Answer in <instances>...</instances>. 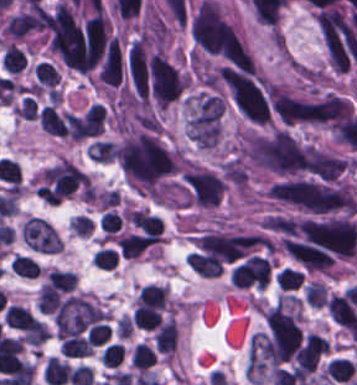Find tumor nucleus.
Listing matches in <instances>:
<instances>
[{
    "label": "tumor nucleus",
    "instance_id": "2f306a5c",
    "mask_svg": "<svg viewBox=\"0 0 357 385\" xmlns=\"http://www.w3.org/2000/svg\"><path fill=\"white\" fill-rule=\"evenodd\" d=\"M114 154L136 191H147L176 168V155L150 132L123 131L114 144Z\"/></svg>",
    "mask_w": 357,
    "mask_h": 385
},
{
    "label": "tumor nucleus",
    "instance_id": "8643909e",
    "mask_svg": "<svg viewBox=\"0 0 357 385\" xmlns=\"http://www.w3.org/2000/svg\"><path fill=\"white\" fill-rule=\"evenodd\" d=\"M225 102L213 91L197 89L185 98V131L200 149H217L222 142Z\"/></svg>",
    "mask_w": 357,
    "mask_h": 385
}]
</instances>
